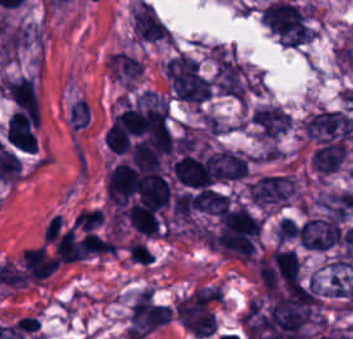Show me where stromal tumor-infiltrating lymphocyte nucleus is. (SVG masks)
<instances>
[{
	"label": "stromal tumor-infiltrating lymphocyte nucleus",
	"mask_w": 353,
	"mask_h": 339,
	"mask_svg": "<svg viewBox=\"0 0 353 339\" xmlns=\"http://www.w3.org/2000/svg\"><path fill=\"white\" fill-rule=\"evenodd\" d=\"M128 257L133 263L142 265H150L154 261V256L149 249L138 241L132 239L129 245L126 247Z\"/></svg>",
	"instance_id": "bc302bb0"
},
{
	"label": "stromal tumor-infiltrating lymphocyte nucleus",
	"mask_w": 353,
	"mask_h": 339,
	"mask_svg": "<svg viewBox=\"0 0 353 339\" xmlns=\"http://www.w3.org/2000/svg\"><path fill=\"white\" fill-rule=\"evenodd\" d=\"M104 221L100 210H83L78 229L94 231Z\"/></svg>",
	"instance_id": "52c7bb5b"
}]
</instances>
